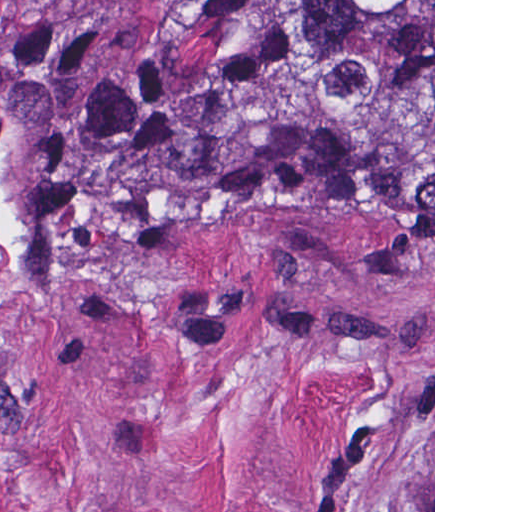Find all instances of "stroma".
Segmentation results:
<instances>
[{
	"label": "stroma",
	"mask_w": 512,
	"mask_h": 512,
	"mask_svg": "<svg viewBox=\"0 0 512 512\" xmlns=\"http://www.w3.org/2000/svg\"><path fill=\"white\" fill-rule=\"evenodd\" d=\"M208 0H0V50ZM0 512H435L433 221L341 166L50 269L0 355Z\"/></svg>",
	"instance_id": "stroma-1"
}]
</instances>
